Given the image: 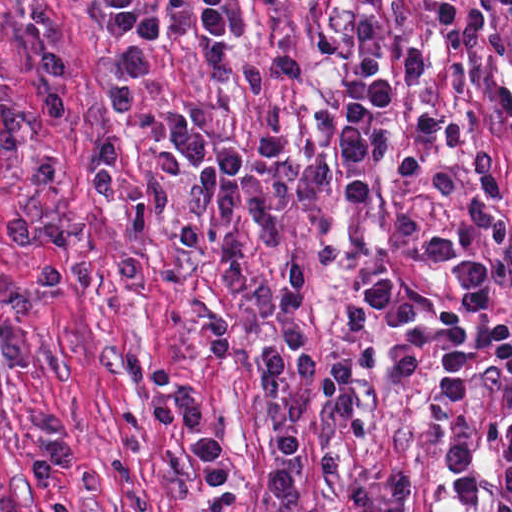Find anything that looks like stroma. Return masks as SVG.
I'll return each mask as SVG.
<instances>
[{
  "label": "stroma",
  "mask_w": 512,
  "mask_h": 512,
  "mask_svg": "<svg viewBox=\"0 0 512 512\" xmlns=\"http://www.w3.org/2000/svg\"><path fill=\"white\" fill-rule=\"evenodd\" d=\"M139 1L163 27L154 82H140L122 67L85 0H0V83L22 100L40 98L42 52L61 44L67 92V113L44 137L64 163L61 178L29 185L22 179V160L0 153V233L15 220L91 230L87 245L56 253L65 285L47 294L33 289L37 248L12 250L0 239V512H342L341 503L366 469L391 454L416 474L413 512H489L487 440L492 416L509 392L507 379L495 372L480 375L472 400L443 422L428 416L383 368L351 377L353 410L370 429L366 441L335 418L316 385L299 424L302 496L294 507L274 499L264 478L273 459L270 433L293 377L288 360L279 388L259 381L249 355L282 320L221 286L218 244H179L184 223L208 232L222 228L208 212L195 219L187 210L184 193L197 169L191 155L163 126L114 124L106 101V85L124 82L134 97L174 108L212 140L241 146L282 215L285 243L270 248L243 224L239 243L261 281H277L290 256L307 260L313 275L297 321L320 355L321 373L339 354L358 349L342 327L341 309L361 286L392 278L398 286L423 287L441 304L464 297L461 282L437 261L427 239L450 224L464 226L467 203L479 192L474 180L426 153L430 168L454 177L452 201L429 197L393 175L398 151L413 141L414 122L435 107L434 85L412 91L405 64V51L419 46L428 64L440 66L426 23L435 0H406L410 19L387 33L397 60L393 144L372 170L365 209L346 207L348 177L343 178L332 214L336 239L348 255L331 269L315 263L308 212L280 207L257 161L265 98L244 76L221 75L207 44L177 23L164 0ZM251 1L260 11V29L254 41L235 48L251 58H297L305 64L306 77L289 92L290 143L300 155L327 157L351 90L359 0ZM498 20L512 42L499 10ZM509 81L512 44L506 54L485 51L481 79L455 102L464 140L445 152L463 164L480 142L498 144L507 192L512 147L488 100L496 85ZM99 141L119 147L125 176L139 169L162 173L170 195L165 214L104 208L94 200L86 170ZM488 297L512 321V276L493 285ZM207 304L245 335L247 353L202 349ZM176 380H187L197 392L205 429L227 443L238 469V481L216 499L196 489L185 424L159 429L149 418L150 399ZM31 410L63 415L70 423L73 469L47 491L27 486L19 471L21 458L42 440L29 420ZM477 434L483 499L468 507L446 477V450Z\"/></svg>",
  "instance_id": "1"
}]
</instances>
